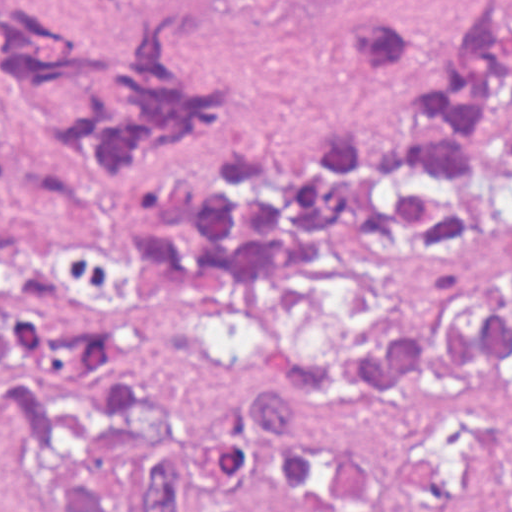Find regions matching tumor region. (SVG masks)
Masks as SVG:
<instances>
[{
  "label": "tumor region",
  "mask_w": 512,
  "mask_h": 512,
  "mask_svg": "<svg viewBox=\"0 0 512 512\" xmlns=\"http://www.w3.org/2000/svg\"><path fill=\"white\" fill-rule=\"evenodd\" d=\"M353 49L421 98L412 124L241 147L204 178L173 162L236 101L243 64L182 0H0V212L123 219L155 287L242 298L266 339L254 391L176 435L136 512H208L328 412L512 388V1L454 44L368 17ZM124 286L113 254L0 219V429L54 512H121L162 445L145 344L88 322ZM443 512H512V457Z\"/></svg>",
  "instance_id": "1"
}]
</instances>
